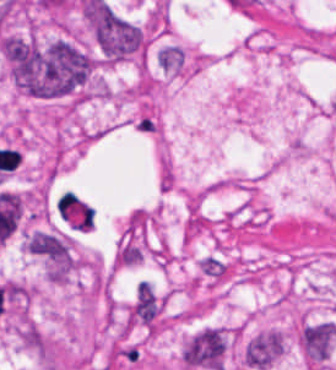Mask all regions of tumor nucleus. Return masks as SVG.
<instances>
[{
    "label": "tumor nucleus",
    "instance_id": "2083b535",
    "mask_svg": "<svg viewBox=\"0 0 336 370\" xmlns=\"http://www.w3.org/2000/svg\"><path fill=\"white\" fill-rule=\"evenodd\" d=\"M183 60L184 55L178 45H164L156 54V62L162 70L177 71Z\"/></svg>",
    "mask_w": 336,
    "mask_h": 370
},
{
    "label": "tumor nucleus",
    "instance_id": "2cbd58db",
    "mask_svg": "<svg viewBox=\"0 0 336 370\" xmlns=\"http://www.w3.org/2000/svg\"><path fill=\"white\" fill-rule=\"evenodd\" d=\"M282 348V338L278 331L268 330L254 334L243 347L244 364L254 370H265L275 360Z\"/></svg>",
    "mask_w": 336,
    "mask_h": 370
},
{
    "label": "tumor nucleus",
    "instance_id": "3d1891a8",
    "mask_svg": "<svg viewBox=\"0 0 336 370\" xmlns=\"http://www.w3.org/2000/svg\"><path fill=\"white\" fill-rule=\"evenodd\" d=\"M335 339L334 326L329 322L309 323L300 331V346L306 357L316 363L328 359Z\"/></svg>",
    "mask_w": 336,
    "mask_h": 370
},
{
    "label": "tumor nucleus",
    "instance_id": "8643909e",
    "mask_svg": "<svg viewBox=\"0 0 336 370\" xmlns=\"http://www.w3.org/2000/svg\"><path fill=\"white\" fill-rule=\"evenodd\" d=\"M83 15L95 47L107 62L141 53L143 31L102 1L87 0Z\"/></svg>",
    "mask_w": 336,
    "mask_h": 370
},
{
    "label": "tumor nucleus",
    "instance_id": "2f306a5c",
    "mask_svg": "<svg viewBox=\"0 0 336 370\" xmlns=\"http://www.w3.org/2000/svg\"><path fill=\"white\" fill-rule=\"evenodd\" d=\"M0 47L15 85L31 96H68L83 89L93 71V57L68 38L6 35Z\"/></svg>",
    "mask_w": 336,
    "mask_h": 370
},
{
    "label": "tumor nucleus",
    "instance_id": "5ab6c2c4",
    "mask_svg": "<svg viewBox=\"0 0 336 370\" xmlns=\"http://www.w3.org/2000/svg\"><path fill=\"white\" fill-rule=\"evenodd\" d=\"M226 338L218 327H205L187 339L180 354L184 365L206 370H221Z\"/></svg>",
    "mask_w": 336,
    "mask_h": 370
}]
</instances>
